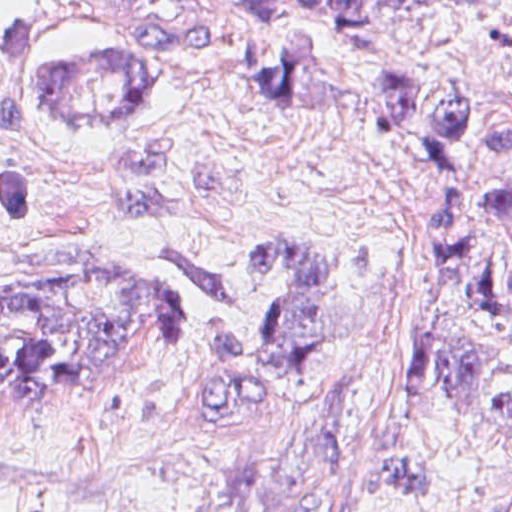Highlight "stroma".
<instances>
[{"label":"stroma","mask_w":512,"mask_h":512,"mask_svg":"<svg viewBox=\"0 0 512 512\" xmlns=\"http://www.w3.org/2000/svg\"><path fill=\"white\" fill-rule=\"evenodd\" d=\"M0 0L55 53L122 51L175 80L144 110H68L0 56V162L35 213L0 225V297L167 282L182 345L48 408L0 418V512H160L314 431L352 443L371 512L512 505V305L477 300L427 223V188L380 117L407 60L481 93L465 190L512 259L493 192L512 127V0L386 13L345 47L324 0ZM287 58L310 102L220 66ZM9 329L0 323V340Z\"/></svg>","instance_id":"35a3bbf8"}]
</instances>
